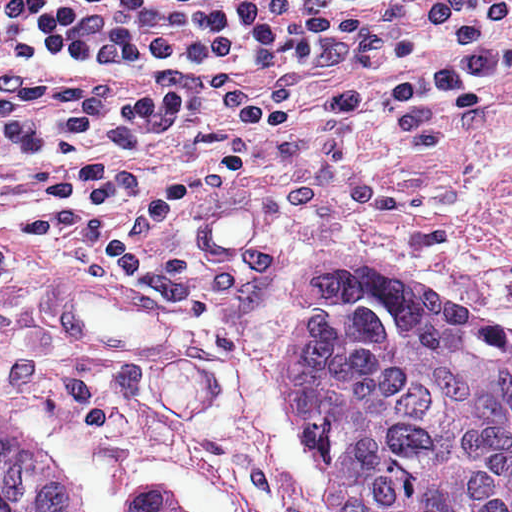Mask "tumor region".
<instances>
[{
	"mask_svg": "<svg viewBox=\"0 0 512 512\" xmlns=\"http://www.w3.org/2000/svg\"><path fill=\"white\" fill-rule=\"evenodd\" d=\"M281 380L332 512H512V328L378 247L303 254ZM0 512H91L0 397ZM122 512H194L146 493Z\"/></svg>",
	"mask_w": 512,
	"mask_h": 512,
	"instance_id": "e687c5a6",
	"label": "tumor region"
}]
</instances>
